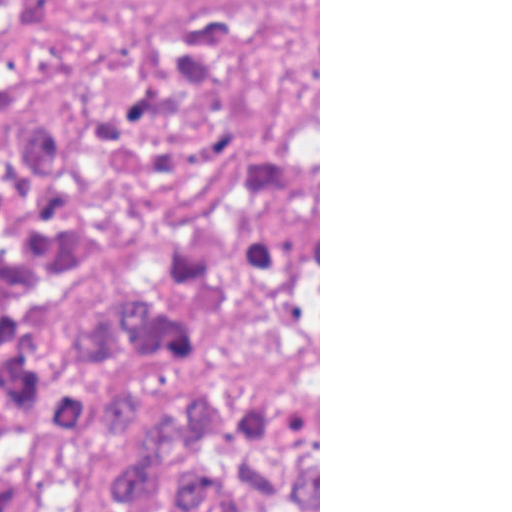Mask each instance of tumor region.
<instances>
[{
    "mask_svg": "<svg viewBox=\"0 0 512 512\" xmlns=\"http://www.w3.org/2000/svg\"><path fill=\"white\" fill-rule=\"evenodd\" d=\"M83 129L0 132V512H318V157L242 162L98 325Z\"/></svg>",
    "mask_w": 512,
    "mask_h": 512,
    "instance_id": "obj_1",
    "label": "tumor region"
}]
</instances>
